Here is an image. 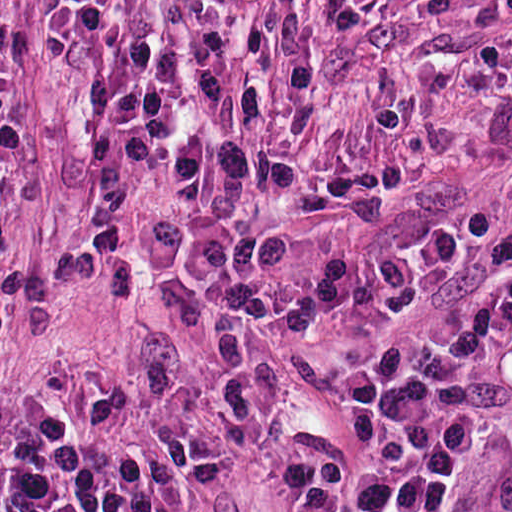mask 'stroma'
<instances>
[{
  "label": "stroma",
  "mask_w": 512,
  "mask_h": 512,
  "mask_svg": "<svg viewBox=\"0 0 512 512\" xmlns=\"http://www.w3.org/2000/svg\"><path fill=\"white\" fill-rule=\"evenodd\" d=\"M512 265V0H0V512L41 412L101 462L176 431L185 512H317L361 367ZM438 512H512V368Z\"/></svg>",
  "instance_id": "35a3bbf8"
}]
</instances>
